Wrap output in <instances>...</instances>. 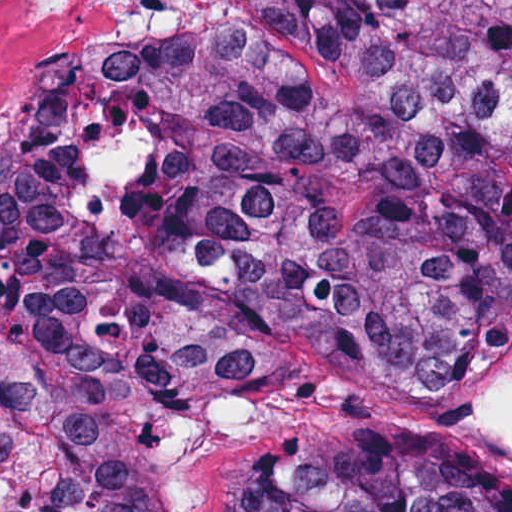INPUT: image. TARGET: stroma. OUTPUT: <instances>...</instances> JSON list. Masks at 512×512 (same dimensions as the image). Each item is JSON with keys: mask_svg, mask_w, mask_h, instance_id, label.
<instances>
[{"mask_svg": "<svg viewBox=\"0 0 512 512\" xmlns=\"http://www.w3.org/2000/svg\"><path fill=\"white\" fill-rule=\"evenodd\" d=\"M178 0L23 133L74 103L113 64L168 20ZM461 382H422L325 351L298 353L264 390L194 442L174 468L176 512H218L234 477L285 438L308 430H407L470 446L512 480V454L452 427L445 409Z\"/></svg>", "mask_w": 512, "mask_h": 512, "instance_id": "1", "label": "stroma"}]
</instances>
